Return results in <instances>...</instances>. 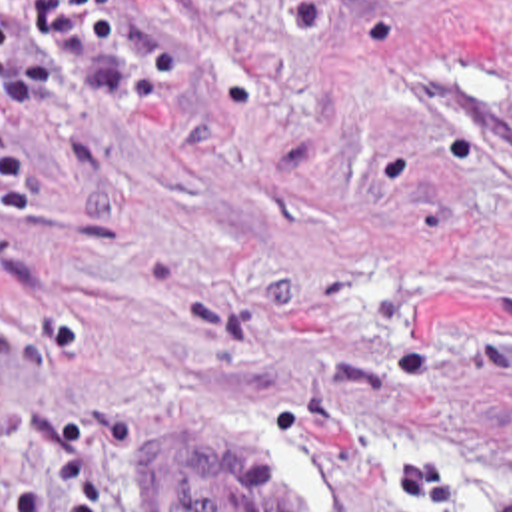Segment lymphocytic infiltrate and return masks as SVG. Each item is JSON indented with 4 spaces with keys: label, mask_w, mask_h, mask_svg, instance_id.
Here are the masks:
<instances>
[{
    "label": "lymphocytic infiltrate",
    "mask_w": 512,
    "mask_h": 512,
    "mask_svg": "<svg viewBox=\"0 0 512 512\" xmlns=\"http://www.w3.org/2000/svg\"><path fill=\"white\" fill-rule=\"evenodd\" d=\"M26 30L66 50L119 48L127 30V0H0V104L40 108L58 94L52 68L32 58Z\"/></svg>",
    "instance_id": "lymphocytic-infiltrate-1"
}]
</instances>
